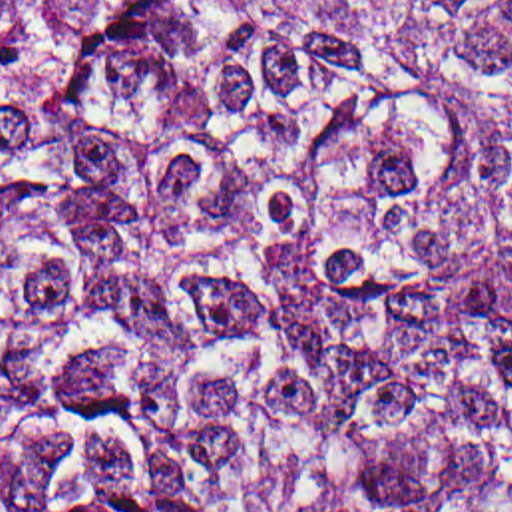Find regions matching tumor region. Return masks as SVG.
Returning <instances> with one entry per match:
<instances>
[{
  "mask_svg": "<svg viewBox=\"0 0 512 512\" xmlns=\"http://www.w3.org/2000/svg\"><path fill=\"white\" fill-rule=\"evenodd\" d=\"M0 512H512V0H0Z\"/></svg>",
  "mask_w": 512,
  "mask_h": 512,
  "instance_id": "e687c5a6",
  "label": "tumor region"
}]
</instances>
